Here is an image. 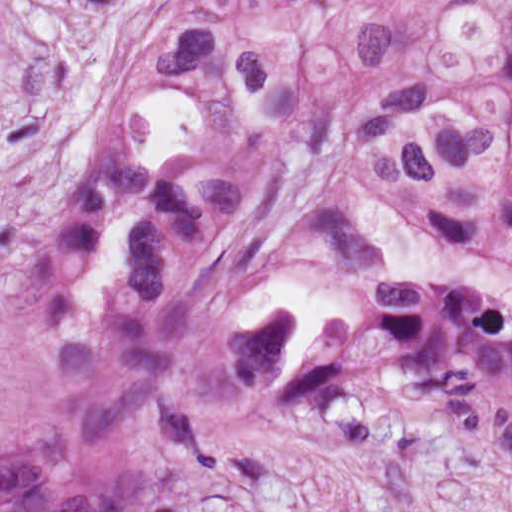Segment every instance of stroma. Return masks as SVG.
I'll list each match as a JSON object with an SVG mask.
<instances>
[{
  "label": "stroma",
  "mask_w": 512,
  "mask_h": 512,
  "mask_svg": "<svg viewBox=\"0 0 512 512\" xmlns=\"http://www.w3.org/2000/svg\"><path fill=\"white\" fill-rule=\"evenodd\" d=\"M171 1L0 0V292L48 265ZM150 512H512V444L372 405L293 404L219 441Z\"/></svg>",
  "instance_id": "35a3bbf8"
}]
</instances>
